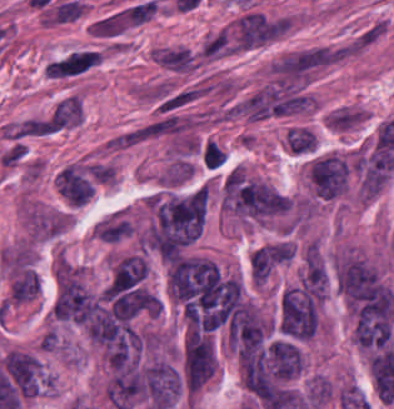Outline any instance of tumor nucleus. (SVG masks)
<instances>
[{
  "mask_svg": "<svg viewBox=\"0 0 394 409\" xmlns=\"http://www.w3.org/2000/svg\"><path fill=\"white\" fill-rule=\"evenodd\" d=\"M301 366L302 356L295 341L273 339L265 346V371L276 384L294 379Z\"/></svg>",
  "mask_w": 394,
  "mask_h": 409,
  "instance_id": "tumor-nucleus-4",
  "label": "tumor nucleus"
},
{
  "mask_svg": "<svg viewBox=\"0 0 394 409\" xmlns=\"http://www.w3.org/2000/svg\"><path fill=\"white\" fill-rule=\"evenodd\" d=\"M320 302L305 285L285 290L279 309V331L293 340H310L319 327Z\"/></svg>",
  "mask_w": 394,
  "mask_h": 409,
  "instance_id": "tumor-nucleus-1",
  "label": "tumor nucleus"
},
{
  "mask_svg": "<svg viewBox=\"0 0 394 409\" xmlns=\"http://www.w3.org/2000/svg\"><path fill=\"white\" fill-rule=\"evenodd\" d=\"M97 306V299L79 282L59 273L53 302L58 319L83 324L92 318Z\"/></svg>",
  "mask_w": 394,
  "mask_h": 409,
  "instance_id": "tumor-nucleus-2",
  "label": "tumor nucleus"
},
{
  "mask_svg": "<svg viewBox=\"0 0 394 409\" xmlns=\"http://www.w3.org/2000/svg\"><path fill=\"white\" fill-rule=\"evenodd\" d=\"M336 287L349 302L366 300L384 288L376 269L355 259L338 265Z\"/></svg>",
  "mask_w": 394,
  "mask_h": 409,
  "instance_id": "tumor-nucleus-3",
  "label": "tumor nucleus"
},
{
  "mask_svg": "<svg viewBox=\"0 0 394 409\" xmlns=\"http://www.w3.org/2000/svg\"><path fill=\"white\" fill-rule=\"evenodd\" d=\"M309 174L316 196L329 200L345 192L346 163L335 155L316 158Z\"/></svg>",
  "mask_w": 394,
  "mask_h": 409,
  "instance_id": "tumor-nucleus-5",
  "label": "tumor nucleus"
}]
</instances>
